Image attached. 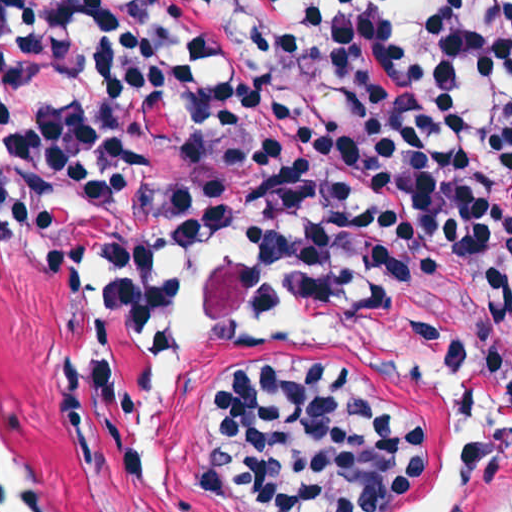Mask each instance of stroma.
<instances>
[{
  "label": "stroma",
  "mask_w": 512,
  "mask_h": 512,
  "mask_svg": "<svg viewBox=\"0 0 512 512\" xmlns=\"http://www.w3.org/2000/svg\"><path fill=\"white\" fill-rule=\"evenodd\" d=\"M79 288L56 285L1 232L0 0V443L21 458L55 512H252L241 499L192 492L206 448L199 409L212 405L224 364L238 353L300 368L363 375L382 400L427 429V459L412 486L384 512H408L440 466L446 415L432 386L336 340L275 337L199 347L176 373L177 428L167 493L146 469L117 471L95 436L88 374L94 292L82 219ZM164 287L178 268H158ZM202 308L225 310L248 281L278 270L320 303L359 311L440 349L464 386L496 407L498 441L455 512L512 509V198H476L436 256L407 268H201ZM143 321L116 360L119 414L142 449L145 427Z\"/></svg>",
  "instance_id": "1"
}]
</instances>
